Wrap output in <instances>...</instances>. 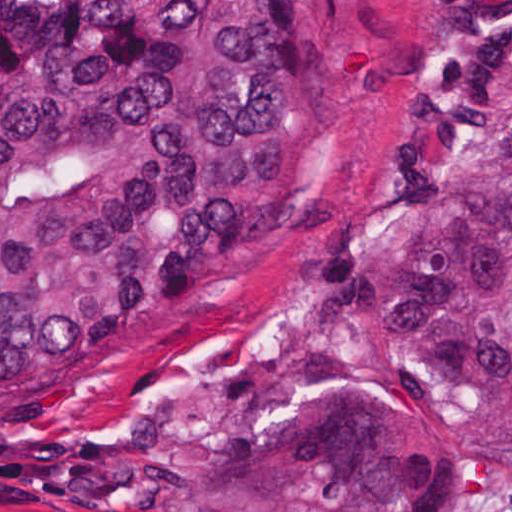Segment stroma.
<instances>
[{
	"label": "stroma",
	"mask_w": 512,
	"mask_h": 512,
	"mask_svg": "<svg viewBox=\"0 0 512 512\" xmlns=\"http://www.w3.org/2000/svg\"><path fill=\"white\" fill-rule=\"evenodd\" d=\"M297 1L301 106L270 209L202 295L151 310L147 332L125 350L0 394V431L163 425L240 356L345 342L329 299L325 228L371 163L384 86L435 58L449 0ZM0 512L85 511L0 493ZM438 512H512V477L467 471Z\"/></svg>",
	"instance_id": "obj_1"
}]
</instances>
